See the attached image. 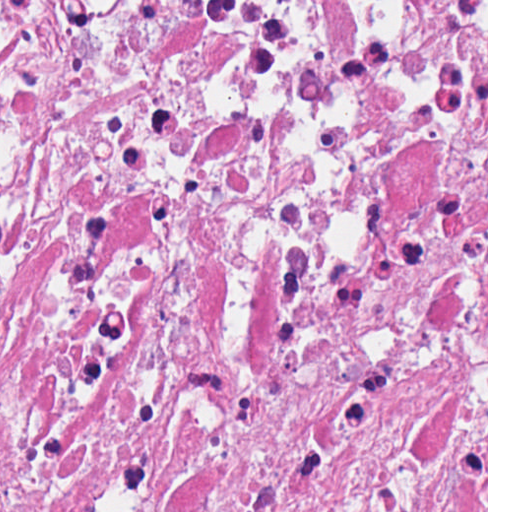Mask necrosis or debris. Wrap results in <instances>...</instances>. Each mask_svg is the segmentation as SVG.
Listing matches in <instances>:
<instances>
[{"label":"necrosis or debris","instance_id":"necrosis-or-debris-1","mask_svg":"<svg viewBox=\"0 0 512 512\" xmlns=\"http://www.w3.org/2000/svg\"><path fill=\"white\" fill-rule=\"evenodd\" d=\"M0 512H486V0H0Z\"/></svg>","mask_w":512,"mask_h":512}]
</instances>
